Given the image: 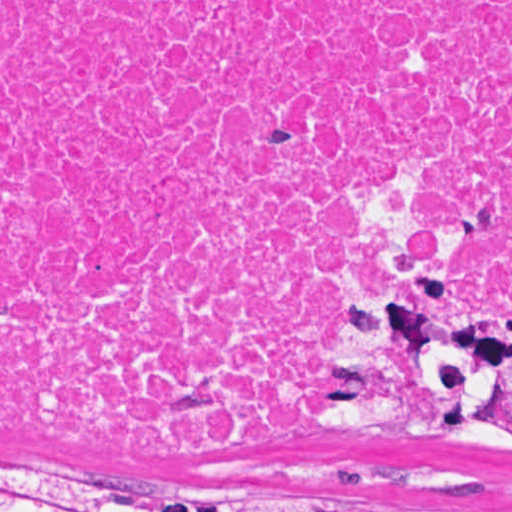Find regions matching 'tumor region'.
<instances>
[{"label": "tumor region", "instance_id": "e687c5a6", "mask_svg": "<svg viewBox=\"0 0 512 512\" xmlns=\"http://www.w3.org/2000/svg\"><path fill=\"white\" fill-rule=\"evenodd\" d=\"M318 360L332 381L323 395L329 425L348 436L512 455V322L441 306L408 255L374 257L356 272L329 314ZM332 507L367 512V495L337 492ZM0 512L331 511L162 503L94 475L0 467Z\"/></svg>", "mask_w": 512, "mask_h": 512}]
</instances>
